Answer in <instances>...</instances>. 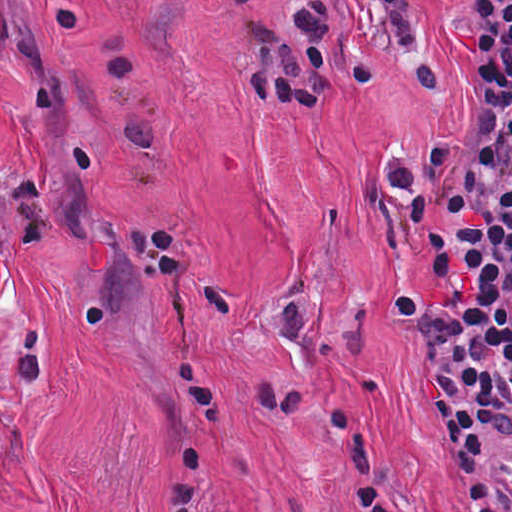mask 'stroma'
Here are the masks:
<instances>
[{
  "label": "stroma",
  "mask_w": 512,
  "mask_h": 512,
  "mask_svg": "<svg viewBox=\"0 0 512 512\" xmlns=\"http://www.w3.org/2000/svg\"><path fill=\"white\" fill-rule=\"evenodd\" d=\"M288 512H466L434 425L430 363L391 326L439 287L384 176L462 144L477 19L415 0L428 69L365 7L324 107H259L235 75L240 12L286 0H60Z\"/></svg>",
  "instance_id": "35a3bbf8"
}]
</instances>
